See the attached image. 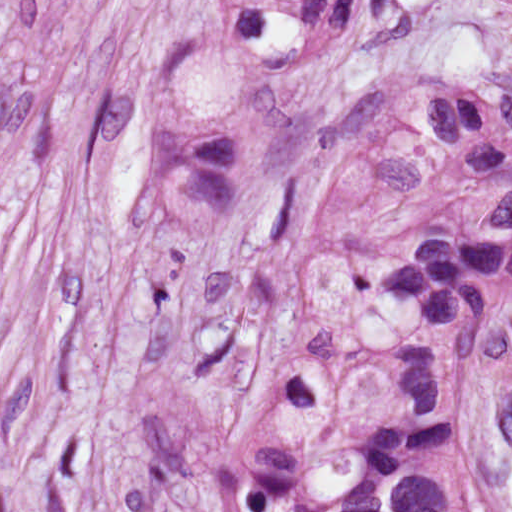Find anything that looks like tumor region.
Wrapping results in <instances>:
<instances>
[{
	"mask_svg": "<svg viewBox=\"0 0 512 512\" xmlns=\"http://www.w3.org/2000/svg\"><path fill=\"white\" fill-rule=\"evenodd\" d=\"M361 2L212 0L156 88L154 230L214 246L258 206L297 98ZM343 118L358 160L311 240L310 296L327 317L399 325L388 385L256 425L148 393L100 450L96 512L181 493L212 512H504L467 419L479 351L512 311V93L393 82Z\"/></svg>",
	"mask_w": 512,
	"mask_h": 512,
	"instance_id": "obj_1",
	"label": "tumor region"
}]
</instances>
